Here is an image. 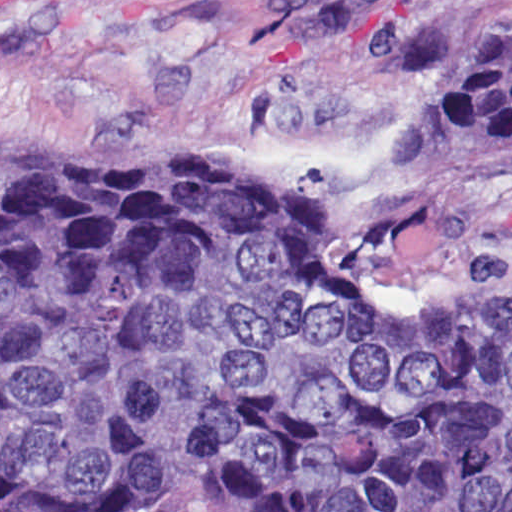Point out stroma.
I'll return each instance as SVG.
<instances>
[{"label":"stroma","mask_w":512,"mask_h":512,"mask_svg":"<svg viewBox=\"0 0 512 512\" xmlns=\"http://www.w3.org/2000/svg\"><path fill=\"white\" fill-rule=\"evenodd\" d=\"M477 1L0 0V166L277 176L367 301L436 313L512 286V148L450 136ZM140 512L248 510L213 484Z\"/></svg>","instance_id":"35a3bbf8"}]
</instances>
